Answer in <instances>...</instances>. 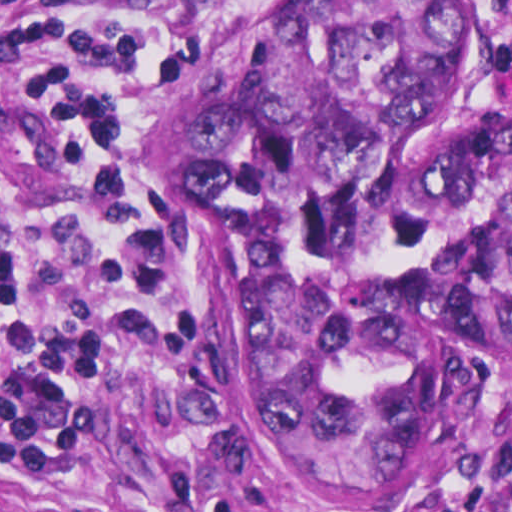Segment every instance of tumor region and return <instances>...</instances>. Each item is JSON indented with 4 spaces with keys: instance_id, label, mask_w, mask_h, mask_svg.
Wrapping results in <instances>:
<instances>
[{
    "instance_id": "e687c5a6",
    "label": "tumor region",
    "mask_w": 512,
    "mask_h": 512,
    "mask_svg": "<svg viewBox=\"0 0 512 512\" xmlns=\"http://www.w3.org/2000/svg\"><path fill=\"white\" fill-rule=\"evenodd\" d=\"M483 59L472 0H300L135 123L221 222L245 436L344 512L439 497L460 397L512 388V115H450Z\"/></svg>"
}]
</instances>
